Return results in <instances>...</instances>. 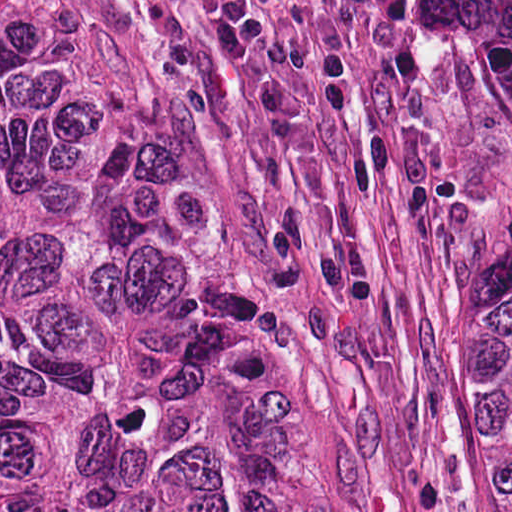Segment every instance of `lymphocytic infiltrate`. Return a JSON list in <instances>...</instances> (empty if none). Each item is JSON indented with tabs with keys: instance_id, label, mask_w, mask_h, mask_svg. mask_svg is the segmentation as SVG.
<instances>
[{
	"instance_id": "obj_1",
	"label": "lymphocytic infiltrate",
	"mask_w": 512,
	"mask_h": 512,
	"mask_svg": "<svg viewBox=\"0 0 512 512\" xmlns=\"http://www.w3.org/2000/svg\"><path fill=\"white\" fill-rule=\"evenodd\" d=\"M348 16L372 11L380 0H313ZM226 46L238 55H254L263 37L259 0H199Z\"/></svg>"
}]
</instances>
